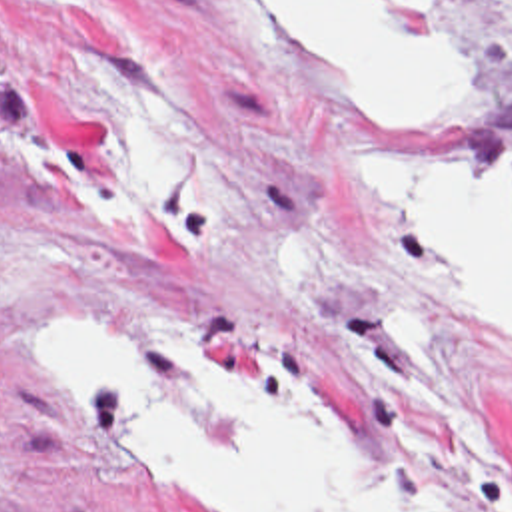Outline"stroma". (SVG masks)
<instances>
[{
	"mask_svg": "<svg viewBox=\"0 0 512 512\" xmlns=\"http://www.w3.org/2000/svg\"><path fill=\"white\" fill-rule=\"evenodd\" d=\"M462 108L376 127L238 0H0V512H220L110 449L48 331L122 335L224 445L194 347L340 413L410 512H512V353L418 283L344 157L512 171V0H458Z\"/></svg>",
	"mask_w": 512,
	"mask_h": 512,
	"instance_id": "1",
	"label": "stroma"
}]
</instances>
